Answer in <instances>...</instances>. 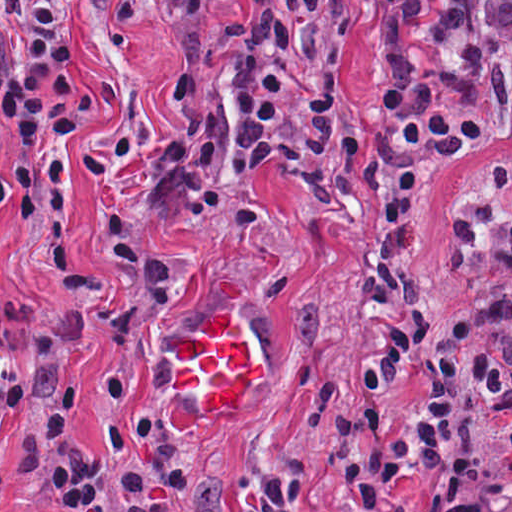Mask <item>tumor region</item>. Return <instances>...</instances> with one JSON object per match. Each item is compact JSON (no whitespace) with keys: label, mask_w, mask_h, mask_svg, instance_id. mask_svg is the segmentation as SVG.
<instances>
[{"label":"tumor region","mask_w":512,"mask_h":512,"mask_svg":"<svg viewBox=\"0 0 512 512\" xmlns=\"http://www.w3.org/2000/svg\"><path fill=\"white\" fill-rule=\"evenodd\" d=\"M166 24L189 49L247 28L265 14V0H154Z\"/></svg>","instance_id":"obj_1"}]
</instances>
